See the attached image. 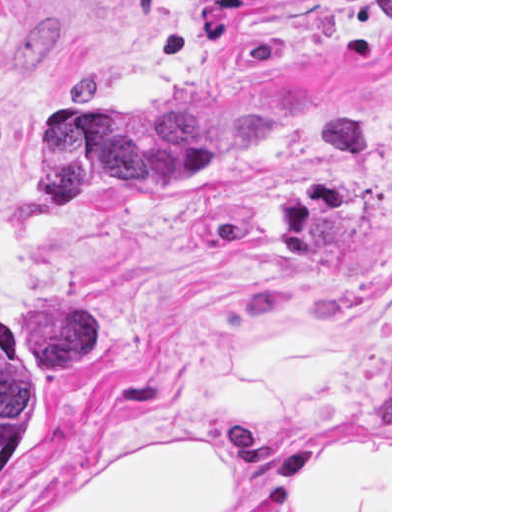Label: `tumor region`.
I'll use <instances>...</instances> for the list:
<instances>
[{
    "instance_id": "1",
    "label": "tumor region",
    "mask_w": 512,
    "mask_h": 512,
    "mask_svg": "<svg viewBox=\"0 0 512 512\" xmlns=\"http://www.w3.org/2000/svg\"><path fill=\"white\" fill-rule=\"evenodd\" d=\"M271 120V101L82 107L51 128L43 149L58 202L81 204L91 184L117 160L155 180L142 162L212 164ZM70 351L69 311L51 306L24 320H0V474L32 420L44 385L60 372Z\"/></svg>"
}]
</instances>
